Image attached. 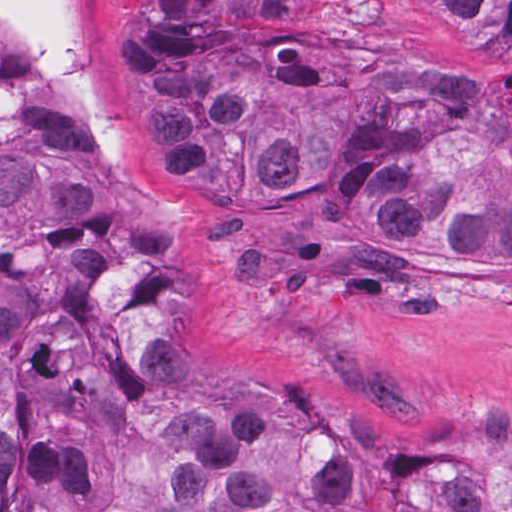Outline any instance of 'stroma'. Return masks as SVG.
Masks as SVG:
<instances>
[{
	"instance_id": "35a3bbf8",
	"label": "stroma",
	"mask_w": 512,
	"mask_h": 512,
	"mask_svg": "<svg viewBox=\"0 0 512 512\" xmlns=\"http://www.w3.org/2000/svg\"><path fill=\"white\" fill-rule=\"evenodd\" d=\"M64 2L116 138L105 155L181 230L200 370L310 420L394 483L449 473L512 486V271L411 264L360 286L304 242L213 213L167 154L126 8Z\"/></svg>"
}]
</instances>
